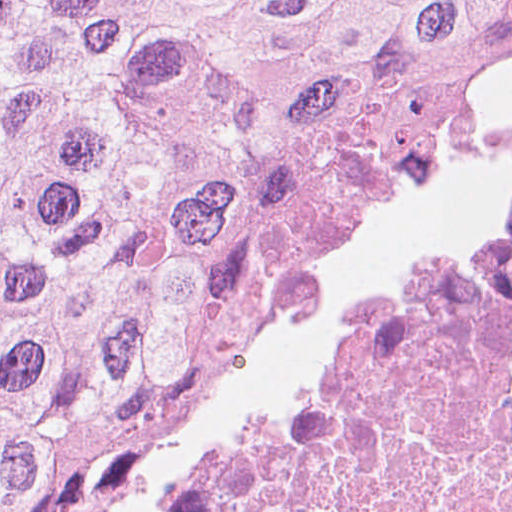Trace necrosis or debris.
Wrapping results in <instances>:
<instances>
[{
	"label": "necrosis or debris",
	"instance_id": "1",
	"mask_svg": "<svg viewBox=\"0 0 512 512\" xmlns=\"http://www.w3.org/2000/svg\"><path fill=\"white\" fill-rule=\"evenodd\" d=\"M151 512H512V178L396 260Z\"/></svg>",
	"mask_w": 512,
	"mask_h": 512
}]
</instances>
